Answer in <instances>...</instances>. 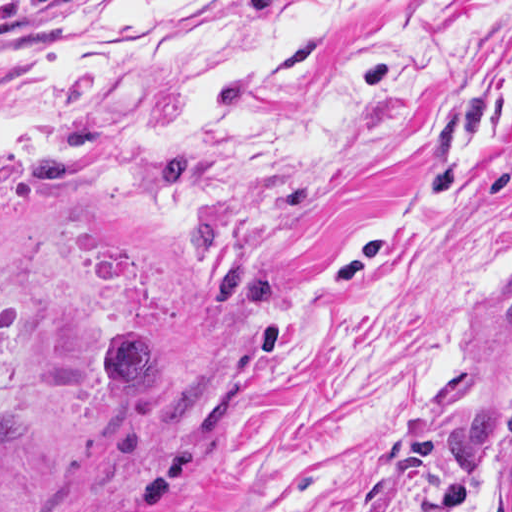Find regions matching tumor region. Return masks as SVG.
Returning <instances> with one entry per match:
<instances>
[{
    "mask_svg": "<svg viewBox=\"0 0 512 512\" xmlns=\"http://www.w3.org/2000/svg\"><path fill=\"white\" fill-rule=\"evenodd\" d=\"M204 174L205 161L198 149L172 146L142 171L138 190L149 199L164 200ZM192 238L203 257L214 256L216 273L226 285L216 302L218 308H232L242 299L271 303L277 298V284L268 275L251 273L238 262L225 266L224 232L218 222L199 220ZM104 351L101 377L112 405L107 434L124 425L130 409L146 398L158 379L167 378V396L157 422L168 436H201L232 409L237 385L213 387V371L207 362L163 358L155 338L145 330L122 329ZM492 440L507 446L499 465V482L512 512V405L484 408L456 426L441 442L434 469L445 497L454 503L464 501L476 490Z\"/></svg>",
    "mask_w": 512,
    "mask_h": 512,
    "instance_id": "tumor-region-1",
    "label": "tumor region"
}]
</instances>
